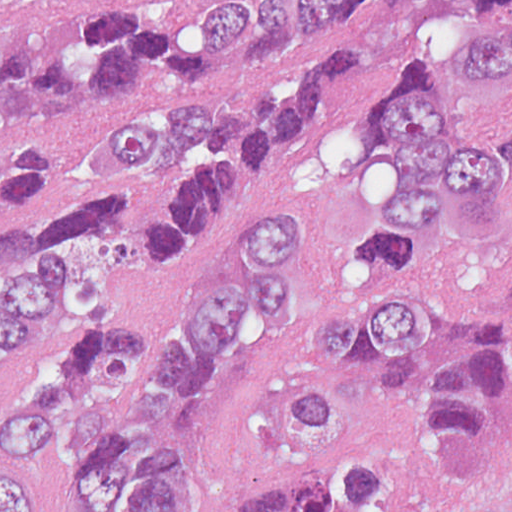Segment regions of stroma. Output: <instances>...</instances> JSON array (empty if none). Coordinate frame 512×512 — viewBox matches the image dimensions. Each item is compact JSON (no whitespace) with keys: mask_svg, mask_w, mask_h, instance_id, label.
Instances as JSON below:
<instances>
[{"mask_svg":"<svg viewBox=\"0 0 512 512\" xmlns=\"http://www.w3.org/2000/svg\"><path fill=\"white\" fill-rule=\"evenodd\" d=\"M0 1H262L260 21L251 35L237 49L221 52L218 68L202 80H183L154 65H136L116 87L99 93L88 110L63 127L32 122L0 100V161L42 136L56 145L63 160L56 193L29 210L78 200L95 170L105 116L128 95L154 84H245L296 49L354 33V70L314 108L300 142L251 213L240 224L158 246L134 225L129 280L98 299L143 300L174 291L246 244L256 218L274 211L297 209L313 222L290 330L277 327L210 425V485L201 512H247L282 457L270 419L274 396L296 385L306 329L337 306L345 288V253L385 177L381 156L365 144V103L381 93L385 75L377 32L362 22L298 18V1L512 0ZM44 512H51L46 505Z\"/></svg>","mask_w":512,"mask_h":512,"instance_id":"35a3bbf8","label":"stroma"}]
</instances>
